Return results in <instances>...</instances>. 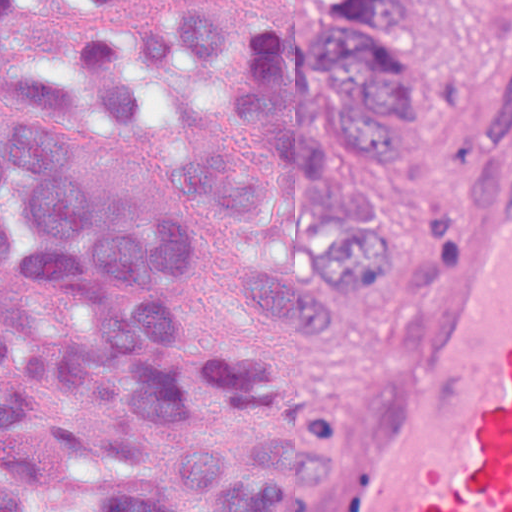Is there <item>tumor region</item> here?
<instances>
[{"label": "tumor region", "mask_w": 512, "mask_h": 512, "mask_svg": "<svg viewBox=\"0 0 512 512\" xmlns=\"http://www.w3.org/2000/svg\"><path fill=\"white\" fill-rule=\"evenodd\" d=\"M38 39L74 60L14 68L0 97V512H301L325 438L283 411L259 351L179 316V222L107 196L61 114L142 135L169 77L193 72L259 123L267 158L217 142L178 150V173L244 223L286 201L329 217L300 258L236 260L293 335L372 200L325 127L386 173L436 44L423 0H322L286 41L241 39L206 13L74 35L0 0V61Z\"/></svg>", "instance_id": "e687c5a6"}]
</instances>
